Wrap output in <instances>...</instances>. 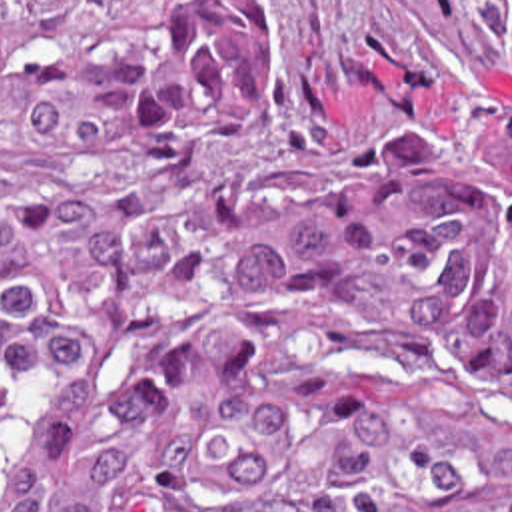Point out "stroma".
<instances>
[{"instance_id": "stroma-1", "label": "stroma", "mask_w": 512, "mask_h": 512, "mask_svg": "<svg viewBox=\"0 0 512 512\" xmlns=\"http://www.w3.org/2000/svg\"><path fill=\"white\" fill-rule=\"evenodd\" d=\"M276 118L240 176H314L414 124H456L460 96L512 118V0H268Z\"/></svg>"}]
</instances>
